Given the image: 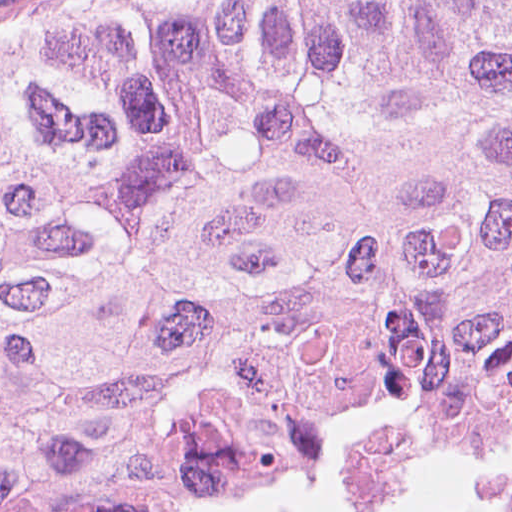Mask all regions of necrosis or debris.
I'll return each mask as SVG.
<instances>
[{"mask_svg": "<svg viewBox=\"0 0 512 512\" xmlns=\"http://www.w3.org/2000/svg\"><path fill=\"white\" fill-rule=\"evenodd\" d=\"M329 512H512V467H463Z\"/></svg>", "mask_w": 512, "mask_h": 512, "instance_id": "4bbe7bcc", "label": "necrosis or debris"}]
</instances>
